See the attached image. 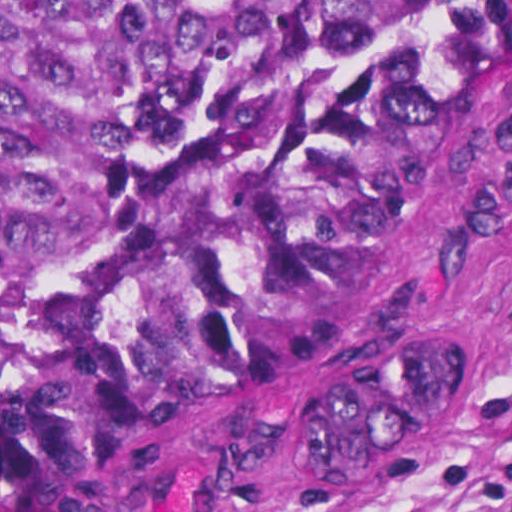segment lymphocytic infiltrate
<instances>
[{"mask_svg":"<svg viewBox=\"0 0 512 512\" xmlns=\"http://www.w3.org/2000/svg\"><path fill=\"white\" fill-rule=\"evenodd\" d=\"M482 415H490L512 424V379L509 381L500 399L486 409Z\"/></svg>","mask_w":512,"mask_h":512,"instance_id":"1","label":"lymphocytic infiltrate"}]
</instances>
